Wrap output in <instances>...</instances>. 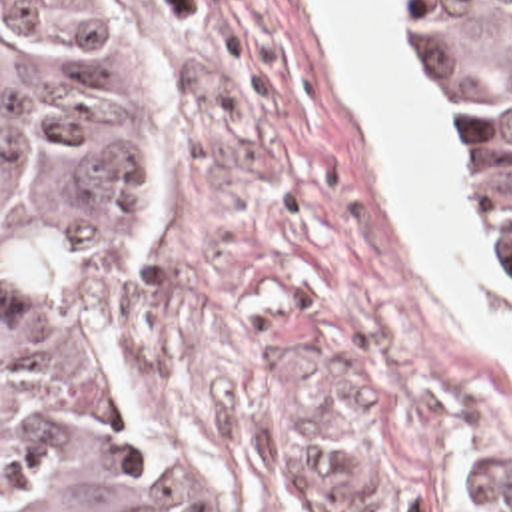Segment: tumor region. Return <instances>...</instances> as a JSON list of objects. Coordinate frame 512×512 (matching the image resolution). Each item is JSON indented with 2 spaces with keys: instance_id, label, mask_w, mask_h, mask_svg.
Returning a JSON list of instances; mask_svg holds the SVG:
<instances>
[{
  "instance_id": "e687c5a6",
  "label": "tumor region",
  "mask_w": 512,
  "mask_h": 512,
  "mask_svg": "<svg viewBox=\"0 0 512 512\" xmlns=\"http://www.w3.org/2000/svg\"><path fill=\"white\" fill-rule=\"evenodd\" d=\"M512 263V0H405ZM116 0H2V512H188L66 367V303L146 221Z\"/></svg>"
}]
</instances>
